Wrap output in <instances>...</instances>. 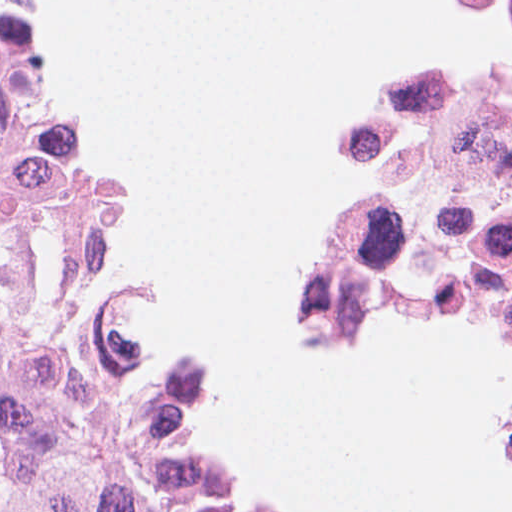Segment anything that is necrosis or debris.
Masks as SVG:
<instances>
[{
  "label": "necrosis or debris",
  "mask_w": 512,
  "mask_h": 512,
  "mask_svg": "<svg viewBox=\"0 0 512 512\" xmlns=\"http://www.w3.org/2000/svg\"><path fill=\"white\" fill-rule=\"evenodd\" d=\"M456 4L512 31V0ZM328 157L374 176V189L320 238L309 322L324 330L360 306L512 319V72L425 80L368 112Z\"/></svg>",
  "instance_id": "1"
}]
</instances>
